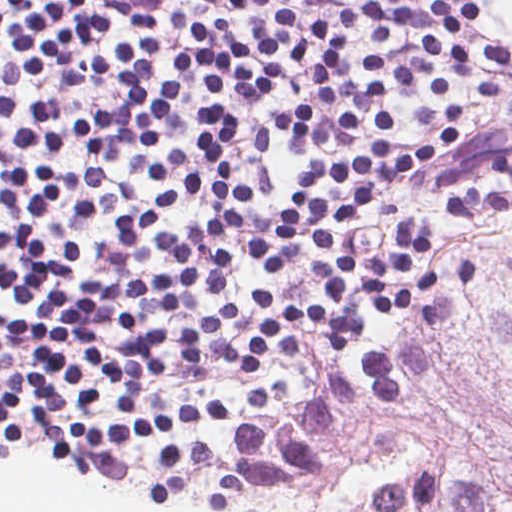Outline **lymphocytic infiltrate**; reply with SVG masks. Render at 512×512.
<instances>
[{
    "label": "lymphocytic infiltrate",
    "mask_w": 512,
    "mask_h": 512,
    "mask_svg": "<svg viewBox=\"0 0 512 512\" xmlns=\"http://www.w3.org/2000/svg\"><path fill=\"white\" fill-rule=\"evenodd\" d=\"M207 19L176 13L187 46L158 68L156 15L133 13L104 43L99 0H0V116L12 152L0 153V327L158 379L245 376V407L280 413L292 394L262 380L269 361L301 351L315 327L349 353L361 335V305L407 312L433 284L477 280L456 263L431 269L429 226L400 217L379 252L359 255L347 231L383 197L464 147L456 104L423 106V143L396 150L391 106L370 102L374 134L353 141L359 122L342 108L341 154L303 167L290 192L270 170L278 134L311 143L317 111L302 102L255 137L251 178L232 171L244 119L223 102H261L284 87L287 60L304 81L335 83L362 29L360 83L373 100L418 88L444 97L485 66H510L504 46L466 33L482 16L473 0H334L311 20L305 0H201ZM60 94L89 76L118 89V108L72 119L57 102L22 94L41 71ZM96 77V78H95ZM210 97L193 141L150 166L152 144L175 89ZM493 175L512 180V139L493 154ZM512 206V193L469 186L449 195V216ZM211 396L219 398L212 394Z\"/></svg>",
    "instance_id": "f902f5d3"
}]
</instances>
